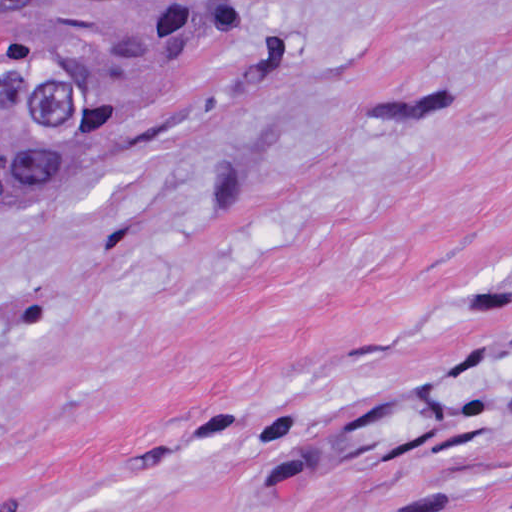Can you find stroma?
I'll return each mask as SVG.
<instances>
[{
    "mask_svg": "<svg viewBox=\"0 0 512 512\" xmlns=\"http://www.w3.org/2000/svg\"><path fill=\"white\" fill-rule=\"evenodd\" d=\"M0 512H512V0H239L0 201Z\"/></svg>",
    "mask_w": 512,
    "mask_h": 512,
    "instance_id": "obj_1",
    "label": "stroma"
}]
</instances>
